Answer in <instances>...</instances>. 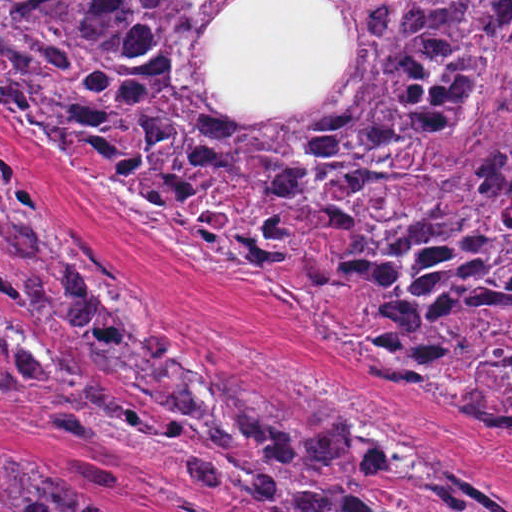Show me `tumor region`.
Returning a JSON list of instances; mask_svg holds the SVG:
<instances>
[{
	"instance_id": "e687c5a6",
	"label": "tumor region",
	"mask_w": 512,
	"mask_h": 512,
	"mask_svg": "<svg viewBox=\"0 0 512 512\" xmlns=\"http://www.w3.org/2000/svg\"><path fill=\"white\" fill-rule=\"evenodd\" d=\"M233 1H0V101L82 180L204 264L286 293L377 376L421 383L512 435V344L425 337L512 329V1H328L351 52L288 109H227L201 64ZM0 297L41 356L0 326V401L67 395L132 455L186 433L211 497L254 512H512L454 458L403 462L321 408L287 414L155 338L125 273L69 218L0 200ZM140 463V460L137 462ZM0 512H106L40 455L0 451Z\"/></svg>"
}]
</instances>
